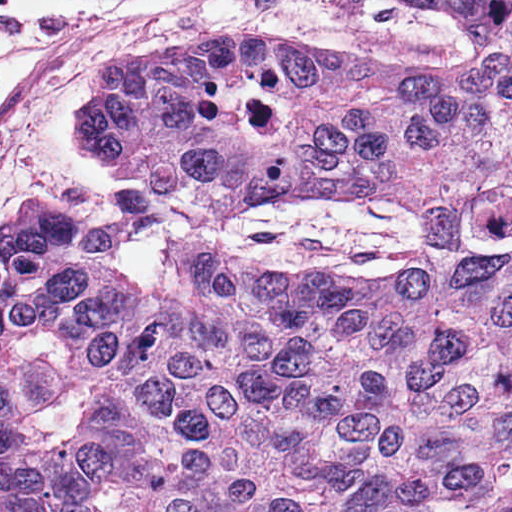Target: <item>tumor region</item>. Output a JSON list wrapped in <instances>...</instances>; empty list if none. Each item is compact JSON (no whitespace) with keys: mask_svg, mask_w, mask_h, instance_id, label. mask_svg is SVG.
Here are the masks:
<instances>
[{"mask_svg":"<svg viewBox=\"0 0 512 512\" xmlns=\"http://www.w3.org/2000/svg\"><path fill=\"white\" fill-rule=\"evenodd\" d=\"M450 64L164 37L75 132L192 210L401 206L409 259L330 285L170 242L142 281L43 198L0 229L3 512H512V0H409Z\"/></svg>","mask_w":512,"mask_h":512,"instance_id":"e687c5a6","label":"tumor region"}]
</instances>
